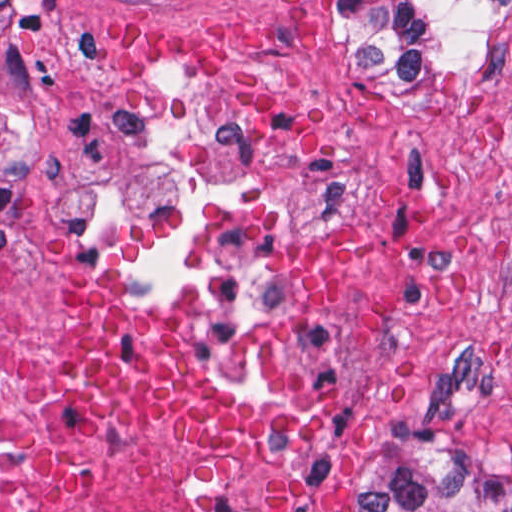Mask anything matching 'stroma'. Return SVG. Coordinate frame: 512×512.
Here are the masks:
<instances>
[{"label":"stroma","instance_id":"stroma-1","mask_svg":"<svg viewBox=\"0 0 512 512\" xmlns=\"http://www.w3.org/2000/svg\"><path fill=\"white\" fill-rule=\"evenodd\" d=\"M0 244L65 406L76 284L264 431L311 512H365L408 416L512 450V0L412 70L330 0H0ZM353 481H356L352 488Z\"/></svg>","mask_w":512,"mask_h":512}]
</instances>
